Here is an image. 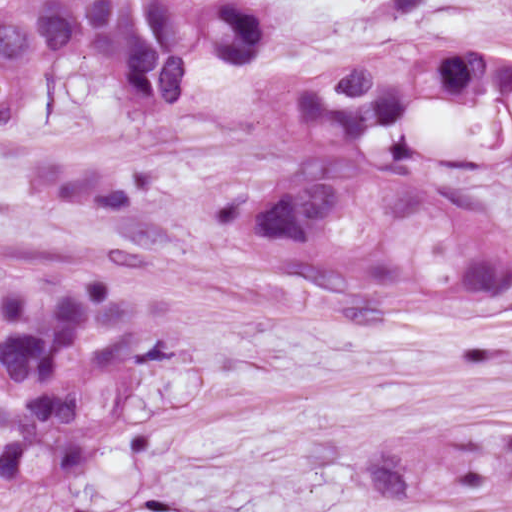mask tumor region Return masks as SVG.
Instances as JSON below:
<instances>
[{"label": "tumor region", "mask_w": 512, "mask_h": 512, "mask_svg": "<svg viewBox=\"0 0 512 512\" xmlns=\"http://www.w3.org/2000/svg\"><path fill=\"white\" fill-rule=\"evenodd\" d=\"M94 477L95 475H92L10 512H73L78 500Z\"/></svg>", "instance_id": "1"}]
</instances>
